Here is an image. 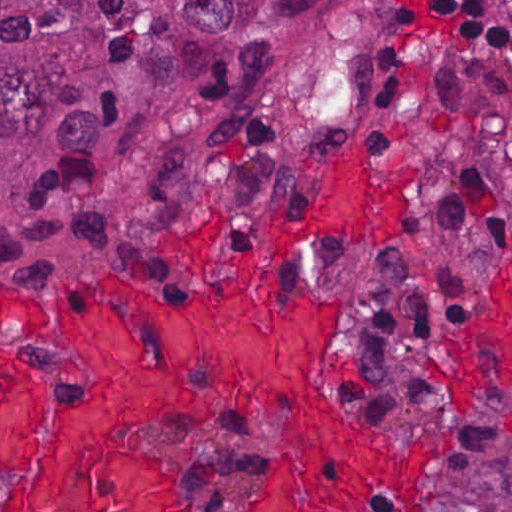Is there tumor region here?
<instances>
[{
  "instance_id": "obj_1",
  "label": "tumor region",
  "mask_w": 512,
  "mask_h": 512,
  "mask_svg": "<svg viewBox=\"0 0 512 512\" xmlns=\"http://www.w3.org/2000/svg\"><path fill=\"white\" fill-rule=\"evenodd\" d=\"M386 3L1 0V260L67 295L103 272L227 276L260 215L303 202L339 138L418 153L399 249L321 246L279 284L346 293L349 408L382 426L436 425L418 366L481 311L476 196L451 159L385 132L371 40ZM471 400L430 475L433 512H512V392L492 383ZM278 432L275 416H238L148 436L176 449L189 512H253Z\"/></svg>"
}]
</instances>
